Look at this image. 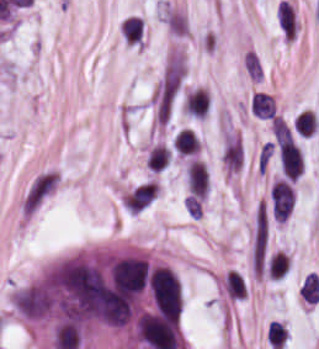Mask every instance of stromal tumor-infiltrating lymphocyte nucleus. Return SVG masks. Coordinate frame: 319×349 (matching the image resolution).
I'll use <instances>...</instances> for the list:
<instances>
[{"mask_svg":"<svg viewBox=\"0 0 319 349\" xmlns=\"http://www.w3.org/2000/svg\"><path fill=\"white\" fill-rule=\"evenodd\" d=\"M278 153L283 175L287 179L296 180L304 167L303 155L299 147L295 143L278 150Z\"/></svg>","mask_w":319,"mask_h":349,"instance_id":"obj_2","label":"stromal tumor-infiltrating lymphocyte nucleus"},{"mask_svg":"<svg viewBox=\"0 0 319 349\" xmlns=\"http://www.w3.org/2000/svg\"><path fill=\"white\" fill-rule=\"evenodd\" d=\"M251 112L270 118L274 115V100L268 93L255 92L251 96Z\"/></svg>","mask_w":319,"mask_h":349,"instance_id":"obj_5","label":"stromal tumor-infiltrating lymphocyte nucleus"},{"mask_svg":"<svg viewBox=\"0 0 319 349\" xmlns=\"http://www.w3.org/2000/svg\"><path fill=\"white\" fill-rule=\"evenodd\" d=\"M184 110L203 118L208 112V93L198 87L190 90L185 98Z\"/></svg>","mask_w":319,"mask_h":349,"instance_id":"obj_3","label":"stromal tumor-infiltrating lymphocyte nucleus"},{"mask_svg":"<svg viewBox=\"0 0 319 349\" xmlns=\"http://www.w3.org/2000/svg\"><path fill=\"white\" fill-rule=\"evenodd\" d=\"M267 338L274 348L281 349L287 338V330L284 324L278 320H271L267 330Z\"/></svg>","mask_w":319,"mask_h":349,"instance_id":"obj_7","label":"stromal tumor-infiltrating lymphocyte nucleus"},{"mask_svg":"<svg viewBox=\"0 0 319 349\" xmlns=\"http://www.w3.org/2000/svg\"><path fill=\"white\" fill-rule=\"evenodd\" d=\"M269 197L274 218L284 222L294 206L295 193L293 188L287 182L274 180Z\"/></svg>","mask_w":319,"mask_h":349,"instance_id":"obj_1","label":"stromal tumor-infiltrating lymphocyte nucleus"},{"mask_svg":"<svg viewBox=\"0 0 319 349\" xmlns=\"http://www.w3.org/2000/svg\"><path fill=\"white\" fill-rule=\"evenodd\" d=\"M173 144L182 153H191L200 146L199 137L190 127H183L176 135Z\"/></svg>","mask_w":319,"mask_h":349,"instance_id":"obj_4","label":"stromal tumor-infiltrating lymphocyte nucleus"},{"mask_svg":"<svg viewBox=\"0 0 319 349\" xmlns=\"http://www.w3.org/2000/svg\"><path fill=\"white\" fill-rule=\"evenodd\" d=\"M289 269L290 258L284 251H277L268 263V271L276 278L284 275Z\"/></svg>","mask_w":319,"mask_h":349,"instance_id":"obj_6","label":"stromal tumor-infiltrating lymphocyte nucleus"}]
</instances>
